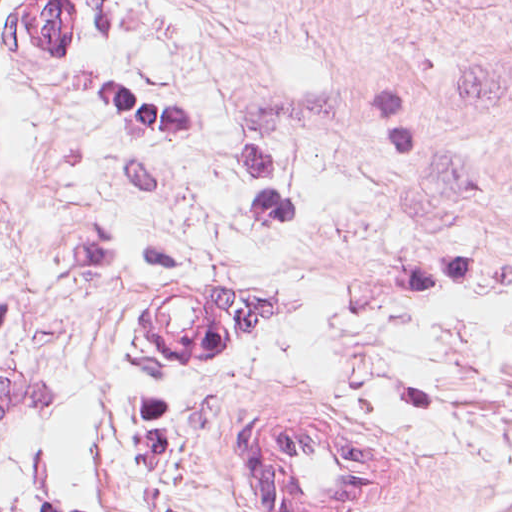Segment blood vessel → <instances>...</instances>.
Masks as SVG:
<instances>
[{
  "mask_svg": "<svg viewBox=\"0 0 512 512\" xmlns=\"http://www.w3.org/2000/svg\"><path fill=\"white\" fill-rule=\"evenodd\" d=\"M27 23L67 53L73 30L66 0H20ZM252 304L195 286L153 298L124 324L127 341L162 368H205L250 323ZM234 415L224 449L263 512H358L390 483L389 459L331 420Z\"/></svg>",
  "mask_w": 512,
  "mask_h": 512,
  "instance_id": "blood-vessel-1",
  "label": "blood vessel"
}]
</instances>
